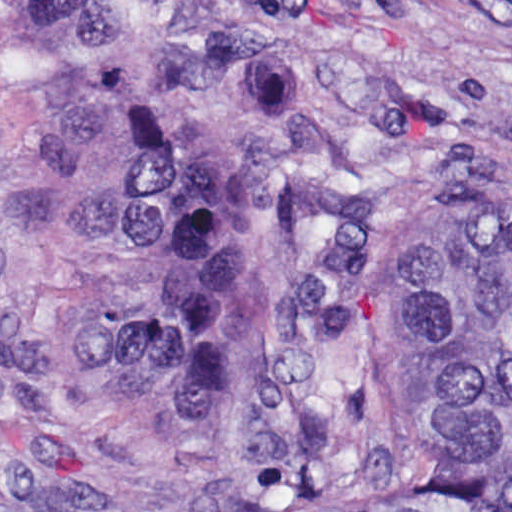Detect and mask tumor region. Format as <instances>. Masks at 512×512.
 <instances>
[{"label":"tumor region","mask_w":512,"mask_h":512,"mask_svg":"<svg viewBox=\"0 0 512 512\" xmlns=\"http://www.w3.org/2000/svg\"><path fill=\"white\" fill-rule=\"evenodd\" d=\"M91 72L92 374L244 450L301 512H512V223L411 257L391 365L419 461L405 482L327 454L379 177L362 71L313 52L308 0H1Z\"/></svg>","instance_id":"1"}]
</instances>
